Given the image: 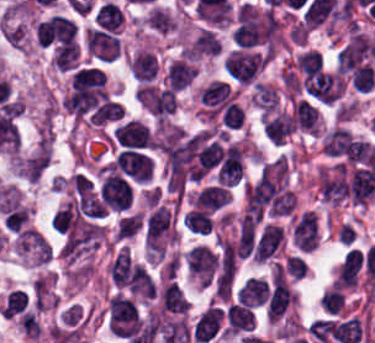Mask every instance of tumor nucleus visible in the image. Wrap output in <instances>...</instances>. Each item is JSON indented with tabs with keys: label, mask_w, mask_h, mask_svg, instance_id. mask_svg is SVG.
<instances>
[{
	"label": "tumor nucleus",
	"mask_w": 375,
	"mask_h": 343,
	"mask_svg": "<svg viewBox=\"0 0 375 343\" xmlns=\"http://www.w3.org/2000/svg\"><path fill=\"white\" fill-rule=\"evenodd\" d=\"M49 164L48 142H41L19 164L20 172L30 180H37Z\"/></svg>",
	"instance_id": "tumor-nucleus-2"
},
{
	"label": "tumor nucleus",
	"mask_w": 375,
	"mask_h": 343,
	"mask_svg": "<svg viewBox=\"0 0 375 343\" xmlns=\"http://www.w3.org/2000/svg\"><path fill=\"white\" fill-rule=\"evenodd\" d=\"M15 241L17 250L42 264L48 261L52 252L43 234L30 227H22L15 236Z\"/></svg>",
	"instance_id": "tumor-nucleus-1"
}]
</instances>
